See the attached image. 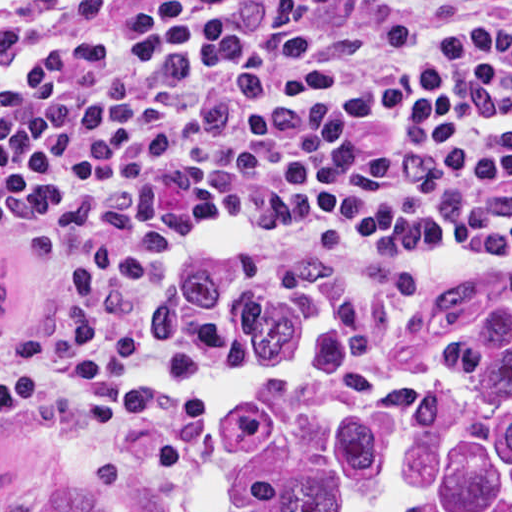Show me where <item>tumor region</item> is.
<instances>
[{"label": "tumor region", "instance_id": "e687c5a6", "mask_svg": "<svg viewBox=\"0 0 512 512\" xmlns=\"http://www.w3.org/2000/svg\"><path fill=\"white\" fill-rule=\"evenodd\" d=\"M0 416V512H512V266H203Z\"/></svg>", "mask_w": 512, "mask_h": 512}]
</instances>
